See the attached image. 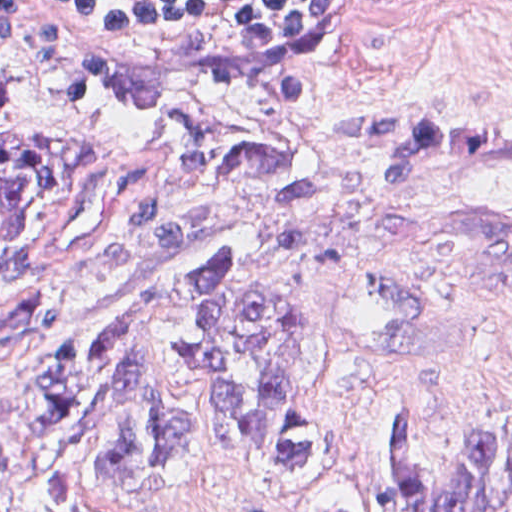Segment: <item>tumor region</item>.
<instances>
[{
    "label": "tumor region",
    "instance_id": "tumor-region-1",
    "mask_svg": "<svg viewBox=\"0 0 512 512\" xmlns=\"http://www.w3.org/2000/svg\"><path fill=\"white\" fill-rule=\"evenodd\" d=\"M343 136L394 184L512 158V103L349 107ZM104 148L51 128L0 79V279L23 282L48 229L87 204ZM325 202L274 135L185 115L152 138L54 275L0 287V512L159 507L216 463L318 494L340 470L318 405L326 272L354 235L512 301V210L466 217ZM437 431L390 412L388 512H512V428L434 464ZM319 512H386L328 493Z\"/></svg>",
    "mask_w": 512,
    "mask_h": 512
}]
</instances>
